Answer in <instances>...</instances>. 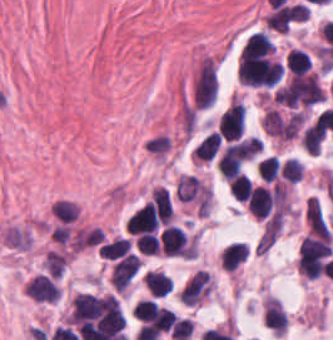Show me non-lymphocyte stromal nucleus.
Listing matches in <instances>:
<instances>
[{
  "label": "non-lymphocyte stromal nucleus",
  "mask_w": 333,
  "mask_h": 340,
  "mask_svg": "<svg viewBox=\"0 0 333 340\" xmlns=\"http://www.w3.org/2000/svg\"><path fill=\"white\" fill-rule=\"evenodd\" d=\"M304 215L310 234L328 238L330 232L318 199L310 196L304 208Z\"/></svg>",
  "instance_id": "dd21d789"
},
{
  "label": "non-lymphocyte stromal nucleus",
  "mask_w": 333,
  "mask_h": 340,
  "mask_svg": "<svg viewBox=\"0 0 333 340\" xmlns=\"http://www.w3.org/2000/svg\"><path fill=\"white\" fill-rule=\"evenodd\" d=\"M29 240L26 231L17 226H10L2 235V242L15 249H28Z\"/></svg>",
  "instance_id": "a72fc3eb"
}]
</instances>
